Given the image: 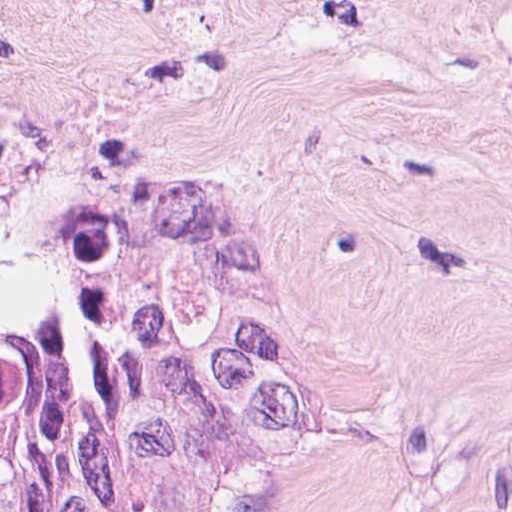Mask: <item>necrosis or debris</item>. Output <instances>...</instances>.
<instances>
[{
  "label": "necrosis or debris",
  "mask_w": 512,
  "mask_h": 512,
  "mask_svg": "<svg viewBox=\"0 0 512 512\" xmlns=\"http://www.w3.org/2000/svg\"><path fill=\"white\" fill-rule=\"evenodd\" d=\"M33 0H0V52L4 41L19 27Z\"/></svg>",
  "instance_id": "obj_1"
}]
</instances>
